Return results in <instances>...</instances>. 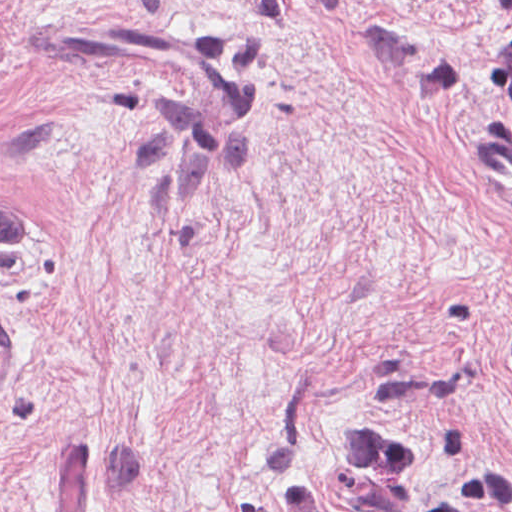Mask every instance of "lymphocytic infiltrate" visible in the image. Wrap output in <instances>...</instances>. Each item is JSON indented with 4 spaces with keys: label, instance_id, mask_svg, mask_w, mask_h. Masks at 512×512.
I'll use <instances>...</instances> for the list:
<instances>
[{
    "label": "lymphocytic infiltrate",
    "instance_id": "lymphocytic-infiltrate-1",
    "mask_svg": "<svg viewBox=\"0 0 512 512\" xmlns=\"http://www.w3.org/2000/svg\"><path fill=\"white\" fill-rule=\"evenodd\" d=\"M512 8V0H493ZM486 94L512 120V38L490 59ZM413 443L377 424L359 428L347 449L350 506L346 512H512V477L482 467L446 495L420 486L413 470ZM288 512H335L317 480L296 475L286 498Z\"/></svg>",
    "mask_w": 512,
    "mask_h": 512
}]
</instances>
